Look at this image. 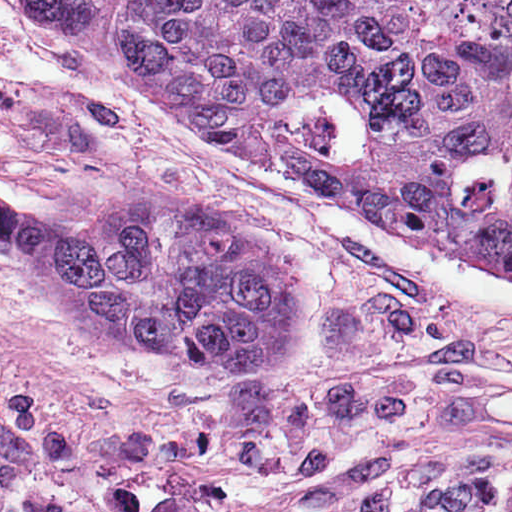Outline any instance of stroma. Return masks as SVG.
<instances>
[{
	"instance_id": "obj_1",
	"label": "stroma",
	"mask_w": 512,
	"mask_h": 512,
	"mask_svg": "<svg viewBox=\"0 0 512 512\" xmlns=\"http://www.w3.org/2000/svg\"><path fill=\"white\" fill-rule=\"evenodd\" d=\"M0 386L27 414L30 455L4 484L6 512H85L0 318Z\"/></svg>"
}]
</instances>
